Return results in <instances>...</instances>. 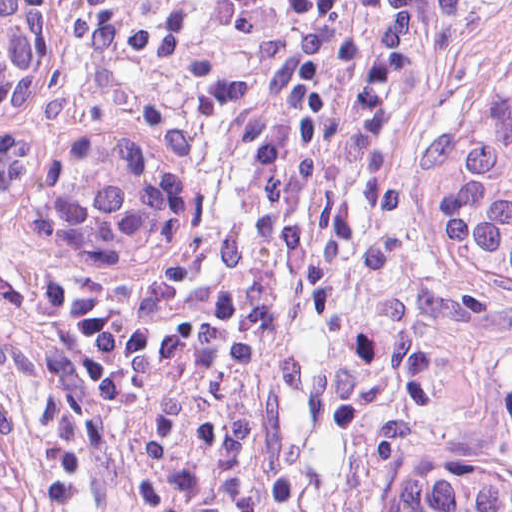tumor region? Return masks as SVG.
Masks as SVG:
<instances>
[{
    "label": "tumor region",
    "instance_id": "obj_1",
    "mask_svg": "<svg viewBox=\"0 0 512 512\" xmlns=\"http://www.w3.org/2000/svg\"><path fill=\"white\" fill-rule=\"evenodd\" d=\"M50 14V76L34 110L0 132L42 142L61 131L106 128L144 137L159 168V229L122 267H72L85 279L81 316L54 385L37 397L0 387L28 440L41 500L59 440V409L81 331L114 302L165 279L190 236L188 177L129 90L105 84ZM418 214L439 257L492 285L512 314V55L440 88L421 110ZM370 512H512V374L491 407L402 472Z\"/></svg>",
    "mask_w": 512,
    "mask_h": 512
}]
</instances>
